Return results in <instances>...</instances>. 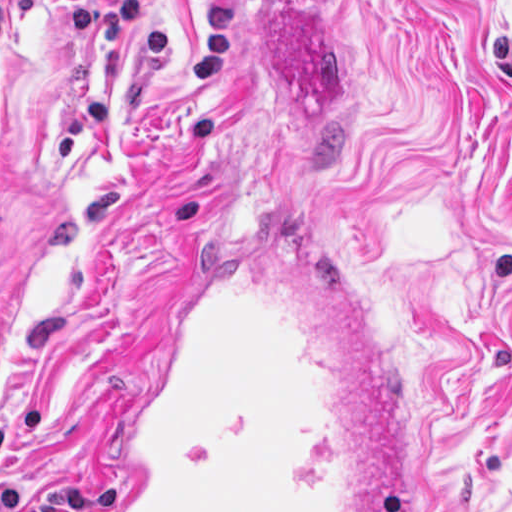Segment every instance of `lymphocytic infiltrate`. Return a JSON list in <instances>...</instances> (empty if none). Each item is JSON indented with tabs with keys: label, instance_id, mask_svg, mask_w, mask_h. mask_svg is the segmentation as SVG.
Instances as JSON below:
<instances>
[{
	"label": "lymphocytic infiltrate",
	"instance_id": "obj_1",
	"mask_svg": "<svg viewBox=\"0 0 512 512\" xmlns=\"http://www.w3.org/2000/svg\"><path fill=\"white\" fill-rule=\"evenodd\" d=\"M2 43V4H0V44ZM23 493L19 485L9 484L0 489V512H19Z\"/></svg>",
	"mask_w": 512,
	"mask_h": 512
}]
</instances>
